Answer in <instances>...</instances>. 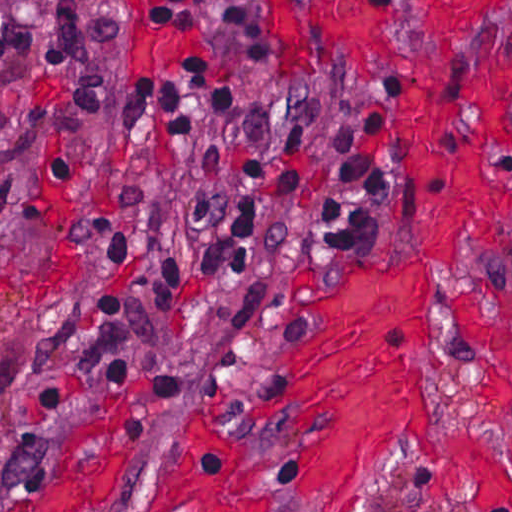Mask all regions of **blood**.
<instances>
[{
    "instance_id": "1a1defca",
    "label": "blood",
    "mask_w": 512,
    "mask_h": 512,
    "mask_svg": "<svg viewBox=\"0 0 512 512\" xmlns=\"http://www.w3.org/2000/svg\"><path fill=\"white\" fill-rule=\"evenodd\" d=\"M142 0L136 63L164 75L206 43L215 63L210 0H187L168 18ZM426 34L443 40L474 24L461 0H426ZM268 49L321 63H362L387 50V28L404 0H256ZM390 108L425 260L456 265L465 231L487 214L512 212V179L485 175L481 150L512 151V115L492 97L486 71L468 75L434 61L395 72ZM440 278L428 261L368 262L330 291L299 297L300 314L324 328L294 339L286 361L292 386L259 411L308 415L299 449L307 498L336 512H359L370 472L402 448L435 465L434 497L512 512V479L470 435L441 432L437 407L415 351L441 365ZM483 373V387L507 424L512 475V290L468 293L447 305ZM172 512H246L252 494L232 469L227 435L210 424L179 435L159 492Z\"/></svg>"
}]
</instances>
